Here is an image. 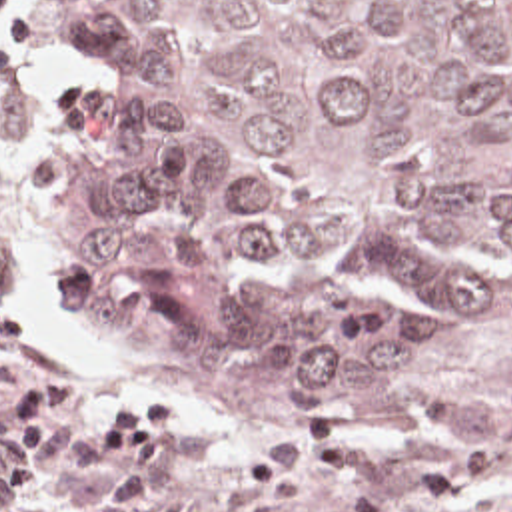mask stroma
Instances as JSON below:
<instances>
[{
  "mask_svg": "<svg viewBox=\"0 0 512 512\" xmlns=\"http://www.w3.org/2000/svg\"><path fill=\"white\" fill-rule=\"evenodd\" d=\"M12 16H32V42L8 48L16 80L0 84V406L24 380L52 370H78L88 380L86 406L72 422H86L132 386H172L188 406V440L164 458L162 490L188 500V512H226L222 492L274 436L340 424L402 454L457 450L475 436L493 448L495 472L435 512H512V294L439 364L427 410H342L282 426H240L164 372L68 322L56 264L78 226L36 210V162L64 126L74 98L104 74L60 12L22 0ZM108 478L110 454L64 446L40 490L28 496L0 490V512H94ZM270 512H344V488L320 482Z\"/></svg>",
  "mask_w": 512,
  "mask_h": 512,
  "instance_id": "35a3bbf8",
  "label": "stroma"
}]
</instances>
